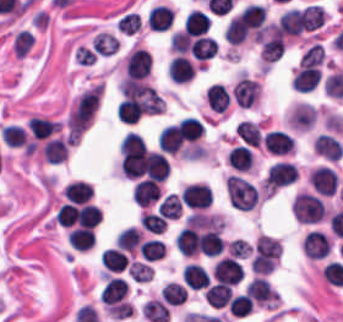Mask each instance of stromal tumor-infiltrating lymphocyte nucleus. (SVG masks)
Wrapping results in <instances>:
<instances>
[{
	"mask_svg": "<svg viewBox=\"0 0 343 322\" xmlns=\"http://www.w3.org/2000/svg\"><path fill=\"white\" fill-rule=\"evenodd\" d=\"M248 296L260 304H270L275 301V294L269 283L261 277H254L245 286Z\"/></svg>",
	"mask_w": 343,
	"mask_h": 322,
	"instance_id": "obj_13",
	"label": "stromal tumor-infiltrating lymphocyte nucleus"
},
{
	"mask_svg": "<svg viewBox=\"0 0 343 322\" xmlns=\"http://www.w3.org/2000/svg\"><path fill=\"white\" fill-rule=\"evenodd\" d=\"M221 229L216 227L201 231L197 240V252L206 257H216L223 252Z\"/></svg>",
	"mask_w": 343,
	"mask_h": 322,
	"instance_id": "obj_9",
	"label": "stromal tumor-infiltrating lymphocyte nucleus"
},
{
	"mask_svg": "<svg viewBox=\"0 0 343 322\" xmlns=\"http://www.w3.org/2000/svg\"><path fill=\"white\" fill-rule=\"evenodd\" d=\"M127 294V283L120 278L108 277L99 297L104 306H117Z\"/></svg>",
	"mask_w": 343,
	"mask_h": 322,
	"instance_id": "obj_10",
	"label": "stromal tumor-infiltrating lymphocyte nucleus"
},
{
	"mask_svg": "<svg viewBox=\"0 0 343 322\" xmlns=\"http://www.w3.org/2000/svg\"><path fill=\"white\" fill-rule=\"evenodd\" d=\"M293 180H295V166L280 160L270 166L263 181V191L273 193Z\"/></svg>",
	"mask_w": 343,
	"mask_h": 322,
	"instance_id": "obj_2",
	"label": "stromal tumor-infiltrating lymphocyte nucleus"
},
{
	"mask_svg": "<svg viewBox=\"0 0 343 322\" xmlns=\"http://www.w3.org/2000/svg\"><path fill=\"white\" fill-rule=\"evenodd\" d=\"M1 140L6 146L20 148L27 144V136L20 126L7 125L0 132Z\"/></svg>",
	"mask_w": 343,
	"mask_h": 322,
	"instance_id": "obj_30",
	"label": "stromal tumor-infiltrating lymphocyte nucleus"
},
{
	"mask_svg": "<svg viewBox=\"0 0 343 322\" xmlns=\"http://www.w3.org/2000/svg\"><path fill=\"white\" fill-rule=\"evenodd\" d=\"M179 197L184 207L205 210L210 206L212 194L205 183L195 182L183 187Z\"/></svg>",
	"mask_w": 343,
	"mask_h": 322,
	"instance_id": "obj_3",
	"label": "stromal tumor-infiltrating lymphocyte nucleus"
},
{
	"mask_svg": "<svg viewBox=\"0 0 343 322\" xmlns=\"http://www.w3.org/2000/svg\"><path fill=\"white\" fill-rule=\"evenodd\" d=\"M204 97L209 107L220 113L226 109L229 102L228 90L218 83L208 85Z\"/></svg>",
	"mask_w": 343,
	"mask_h": 322,
	"instance_id": "obj_20",
	"label": "stromal tumor-infiltrating lymphocyte nucleus"
},
{
	"mask_svg": "<svg viewBox=\"0 0 343 322\" xmlns=\"http://www.w3.org/2000/svg\"><path fill=\"white\" fill-rule=\"evenodd\" d=\"M291 210L297 222L302 225H313L326 215L320 197L310 192H297Z\"/></svg>",
	"mask_w": 343,
	"mask_h": 322,
	"instance_id": "obj_1",
	"label": "stromal tumor-infiltrating lymphocyte nucleus"
},
{
	"mask_svg": "<svg viewBox=\"0 0 343 322\" xmlns=\"http://www.w3.org/2000/svg\"><path fill=\"white\" fill-rule=\"evenodd\" d=\"M217 48V41L205 35H197L189 46L190 53L197 60H205L213 57Z\"/></svg>",
	"mask_w": 343,
	"mask_h": 322,
	"instance_id": "obj_19",
	"label": "stromal tumor-infiltrating lymphocyte nucleus"
},
{
	"mask_svg": "<svg viewBox=\"0 0 343 322\" xmlns=\"http://www.w3.org/2000/svg\"><path fill=\"white\" fill-rule=\"evenodd\" d=\"M140 25L141 21L139 14L132 12H125L115 22L116 30L123 31L131 35L138 31Z\"/></svg>",
	"mask_w": 343,
	"mask_h": 322,
	"instance_id": "obj_35",
	"label": "stromal tumor-infiltrating lymphocyte nucleus"
},
{
	"mask_svg": "<svg viewBox=\"0 0 343 322\" xmlns=\"http://www.w3.org/2000/svg\"><path fill=\"white\" fill-rule=\"evenodd\" d=\"M102 267L111 273H120L128 262L124 252L116 247H109L100 256Z\"/></svg>",
	"mask_w": 343,
	"mask_h": 322,
	"instance_id": "obj_24",
	"label": "stromal tumor-infiltrating lymphocyte nucleus"
},
{
	"mask_svg": "<svg viewBox=\"0 0 343 322\" xmlns=\"http://www.w3.org/2000/svg\"><path fill=\"white\" fill-rule=\"evenodd\" d=\"M140 224L152 234H162L166 228V220L160 214L142 212L140 216Z\"/></svg>",
	"mask_w": 343,
	"mask_h": 322,
	"instance_id": "obj_34",
	"label": "stromal tumor-infiltrating lymphocyte nucleus"
},
{
	"mask_svg": "<svg viewBox=\"0 0 343 322\" xmlns=\"http://www.w3.org/2000/svg\"><path fill=\"white\" fill-rule=\"evenodd\" d=\"M142 238V231L133 226H126L117 234L114 245L121 251L134 252Z\"/></svg>",
	"mask_w": 343,
	"mask_h": 322,
	"instance_id": "obj_23",
	"label": "stromal tumor-infiltrating lymphocyte nucleus"
},
{
	"mask_svg": "<svg viewBox=\"0 0 343 322\" xmlns=\"http://www.w3.org/2000/svg\"><path fill=\"white\" fill-rule=\"evenodd\" d=\"M234 133L244 144L256 148L260 145V132L257 127L248 120H240L235 127Z\"/></svg>",
	"mask_w": 343,
	"mask_h": 322,
	"instance_id": "obj_28",
	"label": "stromal tumor-infiltrating lymphocyte nucleus"
},
{
	"mask_svg": "<svg viewBox=\"0 0 343 322\" xmlns=\"http://www.w3.org/2000/svg\"><path fill=\"white\" fill-rule=\"evenodd\" d=\"M233 294L232 287L223 284L210 285L204 298L208 306L212 309H222L227 306Z\"/></svg>",
	"mask_w": 343,
	"mask_h": 322,
	"instance_id": "obj_18",
	"label": "stromal tumor-infiltrating lymphocyte nucleus"
},
{
	"mask_svg": "<svg viewBox=\"0 0 343 322\" xmlns=\"http://www.w3.org/2000/svg\"><path fill=\"white\" fill-rule=\"evenodd\" d=\"M254 156L248 147L236 145L228 156V163L232 169L238 171H248L251 169Z\"/></svg>",
	"mask_w": 343,
	"mask_h": 322,
	"instance_id": "obj_26",
	"label": "stromal tumor-infiltrating lymphocyte nucleus"
},
{
	"mask_svg": "<svg viewBox=\"0 0 343 322\" xmlns=\"http://www.w3.org/2000/svg\"><path fill=\"white\" fill-rule=\"evenodd\" d=\"M141 311L149 322H169V309L167 305L157 299L145 301Z\"/></svg>",
	"mask_w": 343,
	"mask_h": 322,
	"instance_id": "obj_25",
	"label": "stromal tumor-infiltrating lymphocyte nucleus"
},
{
	"mask_svg": "<svg viewBox=\"0 0 343 322\" xmlns=\"http://www.w3.org/2000/svg\"><path fill=\"white\" fill-rule=\"evenodd\" d=\"M145 261H158L165 254L163 241L147 239L137 249Z\"/></svg>",
	"mask_w": 343,
	"mask_h": 322,
	"instance_id": "obj_31",
	"label": "stromal tumor-infiltrating lymphocyte nucleus"
},
{
	"mask_svg": "<svg viewBox=\"0 0 343 322\" xmlns=\"http://www.w3.org/2000/svg\"><path fill=\"white\" fill-rule=\"evenodd\" d=\"M308 180L315 192L330 197L335 194L337 175L331 166L319 165L308 172Z\"/></svg>",
	"mask_w": 343,
	"mask_h": 322,
	"instance_id": "obj_5",
	"label": "stromal tumor-infiltrating lymphocyte nucleus"
},
{
	"mask_svg": "<svg viewBox=\"0 0 343 322\" xmlns=\"http://www.w3.org/2000/svg\"><path fill=\"white\" fill-rule=\"evenodd\" d=\"M158 194L159 187L146 180H138L131 191V199L136 205L147 208L155 201Z\"/></svg>",
	"mask_w": 343,
	"mask_h": 322,
	"instance_id": "obj_14",
	"label": "stromal tumor-infiltrating lymphocyte nucleus"
},
{
	"mask_svg": "<svg viewBox=\"0 0 343 322\" xmlns=\"http://www.w3.org/2000/svg\"><path fill=\"white\" fill-rule=\"evenodd\" d=\"M182 205L175 195H168L158 206L156 213L164 218L179 219Z\"/></svg>",
	"mask_w": 343,
	"mask_h": 322,
	"instance_id": "obj_32",
	"label": "stromal tumor-infiltrating lymphocyte nucleus"
},
{
	"mask_svg": "<svg viewBox=\"0 0 343 322\" xmlns=\"http://www.w3.org/2000/svg\"><path fill=\"white\" fill-rule=\"evenodd\" d=\"M302 250L306 257L318 261L329 254L330 241L318 230H310L303 239Z\"/></svg>",
	"mask_w": 343,
	"mask_h": 322,
	"instance_id": "obj_8",
	"label": "stromal tumor-infiltrating lymphocyte nucleus"
},
{
	"mask_svg": "<svg viewBox=\"0 0 343 322\" xmlns=\"http://www.w3.org/2000/svg\"><path fill=\"white\" fill-rule=\"evenodd\" d=\"M183 280L189 289H202L209 282V275L205 269L195 263L184 266Z\"/></svg>",
	"mask_w": 343,
	"mask_h": 322,
	"instance_id": "obj_21",
	"label": "stromal tumor-infiltrating lymphocyte nucleus"
},
{
	"mask_svg": "<svg viewBox=\"0 0 343 322\" xmlns=\"http://www.w3.org/2000/svg\"><path fill=\"white\" fill-rule=\"evenodd\" d=\"M263 145L270 154L274 155H283L293 149L291 136L277 129H270L266 132Z\"/></svg>",
	"mask_w": 343,
	"mask_h": 322,
	"instance_id": "obj_12",
	"label": "stromal tumor-infiltrating lymphocyte nucleus"
},
{
	"mask_svg": "<svg viewBox=\"0 0 343 322\" xmlns=\"http://www.w3.org/2000/svg\"><path fill=\"white\" fill-rule=\"evenodd\" d=\"M253 306V302L245 294H238L229 299L227 310L233 317H245Z\"/></svg>",
	"mask_w": 343,
	"mask_h": 322,
	"instance_id": "obj_33",
	"label": "stromal tumor-infiltrating lymphocyte nucleus"
},
{
	"mask_svg": "<svg viewBox=\"0 0 343 322\" xmlns=\"http://www.w3.org/2000/svg\"><path fill=\"white\" fill-rule=\"evenodd\" d=\"M41 155L44 161L57 164L66 159L67 142L57 137L48 139L41 147Z\"/></svg>",
	"mask_w": 343,
	"mask_h": 322,
	"instance_id": "obj_22",
	"label": "stromal tumor-infiltrating lymphocyte nucleus"
},
{
	"mask_svg": "<svg viewBox=\"0 0 343 322\" xmlns=\"http://www.w3.org/2000/svg\"><path fill=\"white\" fill-rule=\"evenodd\" d=\"M174 10L168 5L156 4L147 11L148 30L163 31L173 22Z\"/></svg>",
	"mask_w": 343,
	"mask_h": 322,
	"instance_id": "obj_11",
	"label": "stromal tumor-infiltrating lymphocyte nucleus"
},
{
	"mask_svg": "<svg viewBox=\"0 0 343 322\" xmlns=\"http://www.w3.org/2000/svg\"><path fill=\"white\" fill-rule=\"evenodd\" d=\"M186 294V288L180 283L167 282L163 285L161 298L168 305L179 306L184 302Z\"/></svg>",
	"mask_w": 343,
	"mask_h": 322,
	"instance_id": "obj_29",
	"label": "stromal tumor-infiltrating lymphocyte nucleus"
},
{
	"mask_svg": "<svg viewBox=\"0 0 343 322\" xmlns=\"http://www.w3.org/2000/svg\"><path fill=\"white\" fill-rule=\"evenodd\" d=\"M243 267L234 257H221L213 266L211 275L213 279L227 285H235L240 282Z\"/></svg>",
	"mask_w": 343,
	"mask_h": 322,
	"instance_id": "obj_4",
	"label": "stromal tumor-infiltrating lymphocyte nucleus"
},
{
	"mask_svg": "<svg viewBox=\"0 0 343 322\" xmlns=\"http://www.w3.org/2000/svg\"><path fill=\"white\" fill-rule=\"evenodd\" d=\"M208 26L207 14L197 10H190L183 23L184 31L189 35H201Z\"/></svg>",
	"mask_w": 343,
	"mask_h": 322,
	"instance_id": "obj_27",
	"label": "stromal tumor-infiltrating lymphocyte nucleus"
},
{
	"mask_svg": "<svg viewBox=\"0 0 343 322\" xmlns=\"http://www.w3.org/2000/svg\"><path fill=\"white\" fill-rule=\"evenodd\" d=\"M174 247L179 254L191 256L197 247V232L195 228L183 226L174 238Z\"/></svg>",
	"mask_w": 343,
	"mask_h": 322,
	"instance_id": "obj_17",
	"label": "stromal tumor-infiltrating lymphocyte nucleus"
},
{
	"mask_svg": "<svg viewBox=\"0 0 343 322\" xmlns=\"http://www.w3.org/2000/svg\"><path fill=\"white\" fill-rule=\"evenodd\" d=\"M60 128V122L38 116L28 118V129L34 139H47Z\"/></svg>",
	"mask_w": 343,
	"mask_h": 322,
	"instance_id": "obj_15",
	"label": "stromal tumor-infiltrating lymphocyte nucleus"
},
{
	"mask_svg": "<svg viewBox=\"0 0 343 322\" xmlns=\"http://www.w3.org/2000/svg\"><path fill=\"white\" fill-rule=\"evenodd\" d=\"M151 61L149 55L141 47H134L124 59V72L127 76L143 79L147 76Z\"/></svg>",
	"mask_w": 343,
	"mask_h": 322,
	"instance_id": "obj_7",
	"label": "stromal tumor-infiltrating lymphocyte nucleus"
},
{
	"mask_svg": "<svg viewBox=\"0 0 343 322\" xmlns=\"http://www.w3.org/2000/svg\"><path fill=\"white\" fill-rule=\"evenodd\" d=\"M259 91L257 81L246 75H239L231 89L233 101L238 106L248 108L255 102Z\"/></svg>",
	"mask_w": 343,
	"mask_h": 322,
	"instance_id": "obj_6",
	"label": "stromal tumor-infiltrating lymphocyte nucleus"
},
{
	"mask_svg": "<svg viewBox=\"0 0 343 322\" xmlns=\"http://www.w3.org/2000/svg\"><path fill=\"white\" fill-rule=\"evenodd\" d=\"M168 76L175 83H182L194 76L195 68L190 60L184 56H177L167 67Z\"/></svg>",
	"mask_w": 343,
	"mask_h": 322,
	"instance_id": "obj_16",
	"label": "stromal tumor-infiltrating lymphocyte nucleus"
}]
</instances>
